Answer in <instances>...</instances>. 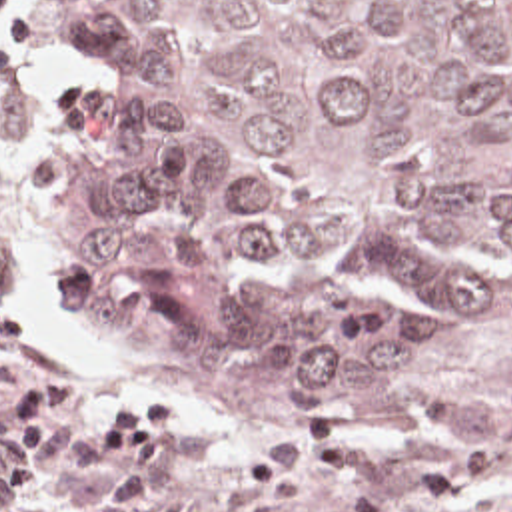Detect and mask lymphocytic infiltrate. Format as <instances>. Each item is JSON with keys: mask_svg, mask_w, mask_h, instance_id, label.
I'll use <instances>...</instances> for the list:
<instances>
[{"mask_svg": "<svg viewBox=\"0 0 512 512\" xmlns=\"http://www.w3.org/2000/svg\"><path fill=\"white\" fill-rule=\"evenodd\" d=\"M22 0H0V84L16 80L8 48L32 42V16H12ZM88 380L78 370L30 376L0 406V490L28 496L54 472L58 450L110 454V478L94 512H188V500L162 490V464L188 440V406L164 384H138L112 396L86 422Z\"/></svg>", "mask_w": 512, "mask_h": 512, "instance_id": "obj_1", "label": "lymphocytic infiltrate"}]
</instances>
